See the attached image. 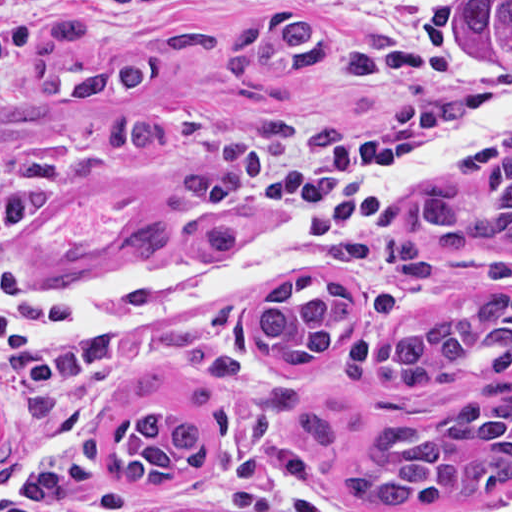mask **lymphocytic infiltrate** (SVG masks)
Returning <instances> with one entry per match:
<instances>
[{
    "label": "lymphocytic infiltrate",
    "mask_w": 512,
    "mask_h": 512,
    "mask_svg": "<svg viewBox=\"0 0 512 512\" xmlns=\"http://www.w3.org/2000/svg\"><path fill=\"white\" fill-rule=\"evenodd\" d=\"M212 151L215 166L228 182L268 196L286 215L317 229L340 226L373 210L378 189L400 161L390 146L371 138L320 130L300 136L259 118L222 126ZM19 215L20 203L0 193V250ZM388 217L363 235L341 262L375 264ZM54 288L8 281L0 274V291ZM65 331L51 317L0 312V360L19 383L66 385L88 373L95 360L87 348L65 346L48 336Z\"/></svg>",
    "instance_id": "lymphocytic-infiltrate-1"
}]
</instances>
